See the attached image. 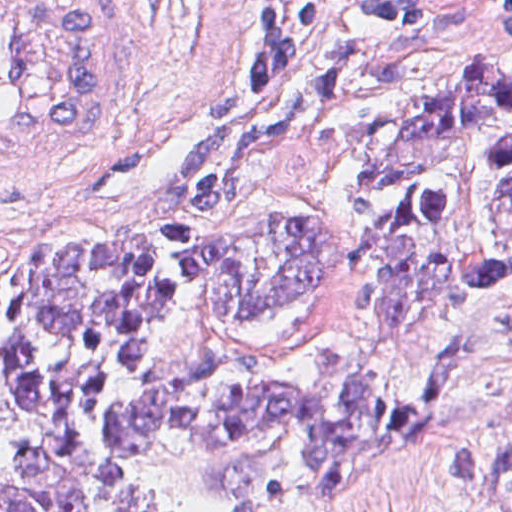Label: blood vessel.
<instances>
[{"instance_id": "blood-vessel-1", "label": "blood vessel", "mask_w": 512, "mask_h": 512, "mask_svg": "<svg viewBox=\"0 0 512 512\" xmlns=\"http://www.w3.org/2000/svg\"><path fill=\"white\" fill-rule=\"evenodd\" d=\"M140 94L141 1H0V190L49 183Z\"/></svg>"}]
</instances>
